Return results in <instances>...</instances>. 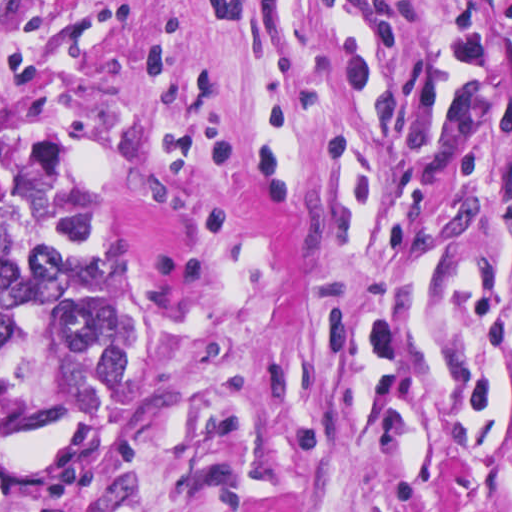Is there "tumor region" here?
Instances as JSON below:
<instances>
[{"instance_id":"tumor-region-1","label":"tumor region","mask_w":512,"mask_h":512,"mask_svg":"<svg viewBox=\"0 0 512 512\" xmlns=\"http://www.w3.org/2000/svg\"><path fill=\"white\" fill-rule=\"evenodd\" d=\"M124 375L118 266L66 180L0 195V512H111L100 469Z\"/></svg>"}]
</instances>
